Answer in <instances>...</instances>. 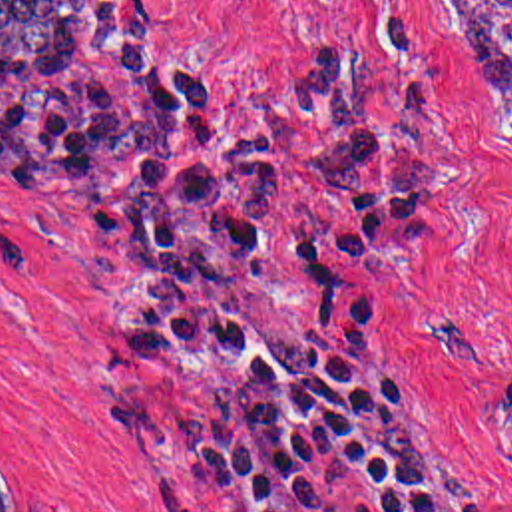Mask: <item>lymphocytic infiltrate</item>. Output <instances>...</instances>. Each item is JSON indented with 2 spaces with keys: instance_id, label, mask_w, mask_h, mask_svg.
<instances>
[{
  "instance_id": "lymphocytic-infiltrate-1",
  "label": "lymphocytic infiltrate",
  "mask_w": 512,
  "mask_h": 512,
  "mask_svg": "<svg viewBox=\"0 0 512 512\" xmlns=\"http://www.w3.org/2000/svg\"><path fill=\"white\" fill-rule=\"evenodd\" d=\"M390 75L434 135L446 53L416 7H378ZM360 73L300 57L282 97L304 137L314 197L278 272L290 336V420L254 512H458L378 380V304L394 278L392 234L428 225L442 187L434 151L378 135Z\"/></svg>"
}]
</instances>
